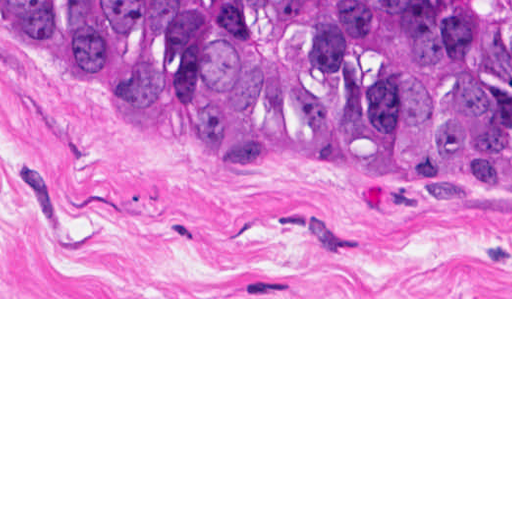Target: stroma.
<instances>
[{
    "label": "stroma",
    "instance_id": "35a3bbf8",
    "mask_svg": "<svg viewBox=\"0 0 512 512\" xmlns=\"http://www.w3.org/2000/svg\"><path fill=\"white\" fill-rule=\"evenodd\" d=\"M0 299H512V161L300 160L0 35Z\"/></svg>",
    "mask_w": 512,
    "mask_h": 512
}]
</instances>
